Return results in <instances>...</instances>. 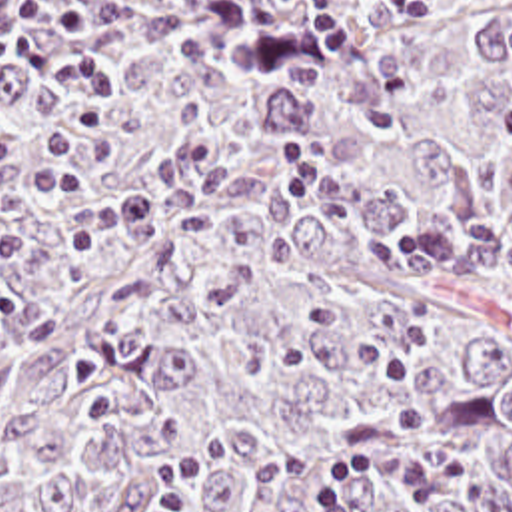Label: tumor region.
<instances>
[{
  "label": "tumor region",
  "mask_w": 512,
  "mask_h": 512,
  "mask_svg": "<svg viewBox=\"0 0 512 512\" xmlns=\"http://www.w3.org/2000/svg\"><path fill=\"white\" fill-rule=\"evenodd\" d=\"M0 63V512H313L409 445L512 512V0H43Z\"/></svg>",
  "instance_id": "1"
}]
</instances>
